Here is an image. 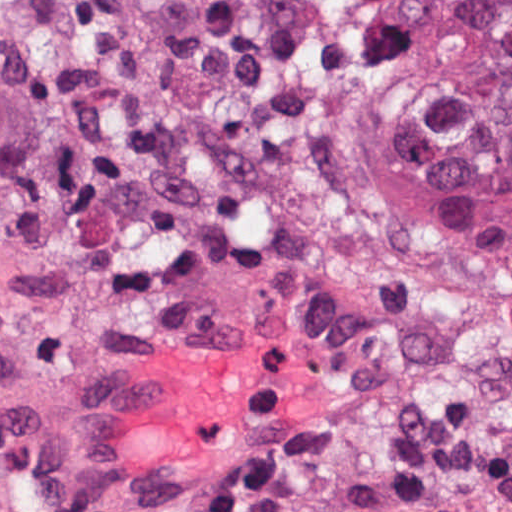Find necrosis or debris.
I'll return each instance as SVG.
<instances>
[{
  "label": "necrosis or debris",
  "instance_id": "4bbe7bcc",
  "mask_svg": "<svg viewBox=\"0 0 512 512\" xmlns=\"http://www.w3.org/2000/svg\"><path fill=\"white\" fill-rule=\"evenodd\" d=\"M426 0H0V382L264 312L335 392L241 512H512V272L378 159Z\"/></svg>",
  "mask_w": 512,
  "mask_h": 512
}]
</instances>
